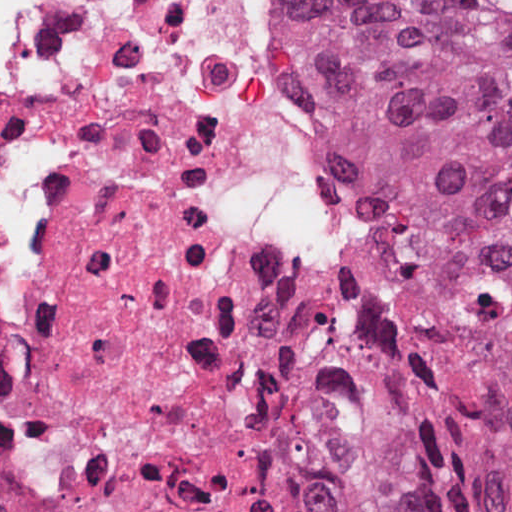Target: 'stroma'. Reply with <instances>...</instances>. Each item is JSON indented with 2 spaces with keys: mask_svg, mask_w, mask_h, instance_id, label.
<instances>
[{
  "mask_svg": "<svg viewBox=\"0 0 512 512\" xmlns=\"http://www.w3.org/2000/svg\"><path fill=\"white\" fill-rule=\"evenodd\" d=\"M281 7L282 13V70L284 73L285 80L291 90L290 77L288 71L291 47H292V17L289 8L288 0H278ZM292 92V90H291ZM348 173V172H347ZM349 174V173H348ZM350 175V174H349ZM351 176V175H350ZM352 177V176H351ZM352 179L358 183L353 177ZM359 184V183H358ZM360 185V184H359ZM373 212V233H374V268L367 278L359 287L355 290L347 293V305L344 312L336 314L334 316L320 320L315 325H319L328 329H332L340 332L356 333L360 334L363 328L368 323L367 314L362 308L359 300L367 281L384 265L385 254L387 249L388 236L384 220L372 209ZM282 388L285 398V403L290 419V425L292 431L295 433L297 439L304 444L319 464L322 465L326 473L329 475L333 483L335 484L329 470L323 463L322 459L305 443L303 437L296 427L295 417L293 413L291 397L289 392L285 361L283 362L282 370ZM336 486V484H335Z\"/></svg>",
  "mask_w": 512,
  "mask_h": 512,
  "instance_id": "stroma-1",
  "label": "stroma"
}]
</instances>
